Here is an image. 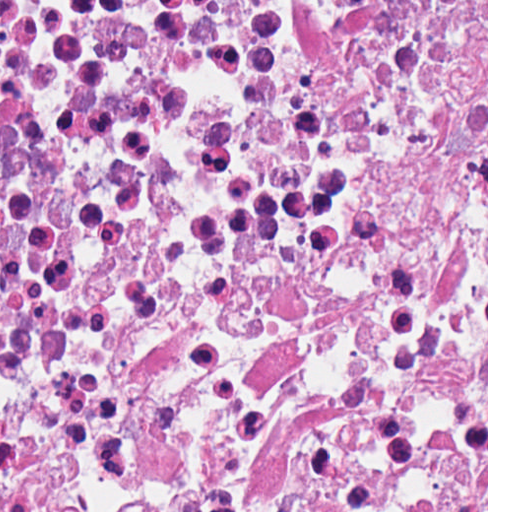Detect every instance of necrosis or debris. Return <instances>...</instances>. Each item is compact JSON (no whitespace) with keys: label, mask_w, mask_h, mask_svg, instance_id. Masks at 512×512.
Here are the masks:
<instances>
[{"label":"necrosis or debris","mask_w":512,"mask_h":512,"mask_svg":"<svg viewBox=\"0 0 512 512\" xmlns=\"http://www.w3.org/2000/svg\"><path fill=\"white\" fill-rule=\"evenodd\" d=\"M0 512H486V0H0Z\"/></svg>","instance_id":"obj_1"}]
</instances>
